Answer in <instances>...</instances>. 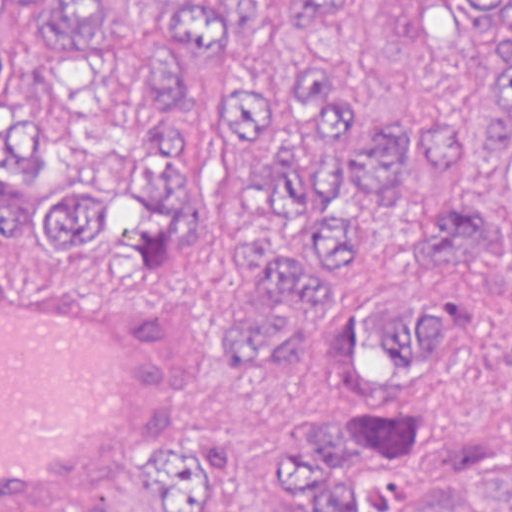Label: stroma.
<instances>
[{
	"instance_id": "1",
	"label": "stroma",
	"mask_w": 512,
	"mask_h": 512,
	"mask_svg": "<svg viewBox=\"0 0 512 512\" xmlns=\"http://www.w3.org/2000/svg\"><path fill=\"white\" fill-rule=\"evenodd\" d=\"M361 2L351 22L331 29L339 69L393 117L408 123L453 119L463 100L460 80L433 45L441 0ZM205 142L213 226L197 265L182 277L138 281L108 249L89 262L52 265L37 245L0 255V268L49 265L78 283H184L202 291L215 318V376L190 430L173 443L231 447L237 493L229 512H282L275 500L279 456L298 418L319 406H369L406 417V426L423 440L422 494L460 457L511 452L512 267L501 261L421 269L413 250L417 224L402 214L382 217L371 232L363 278L372 296L430 319L440 335L421 376L406 387L383 390L346 371L342 349L350 304L347 286L339 282L325 283L310 324L288 355L269 363L224 355L220 333L228 251L240 216V163L206 97ZM473 175L488 194L512 207L511 179L492 166Z\"/></svg>"
}]
</instances>
